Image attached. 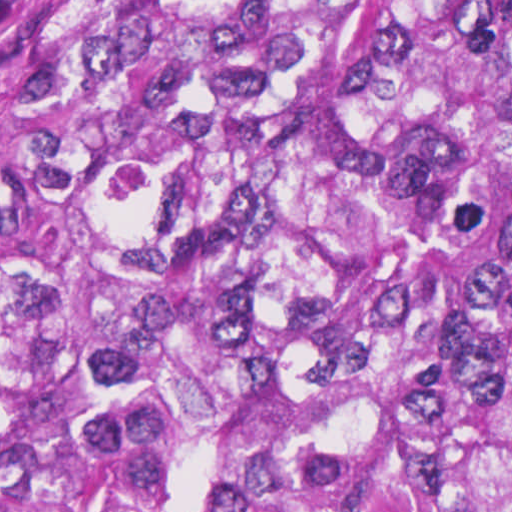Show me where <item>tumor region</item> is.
Segmentation results:
<instances>
[{"label": "tumor region", "mask_w": 512, "mask_h": 512, "mask_svg": "<svg viewBox=\"0 0 512 512\" xmlns=\"http://www.w3.org/2000/svg\"><path fill=\"white\" fill-rule=\"evenodd\" d=\"M0 512H512V0H48Z\"/></svg>", "instance_id": "e687c5a6"}]
</instances>
